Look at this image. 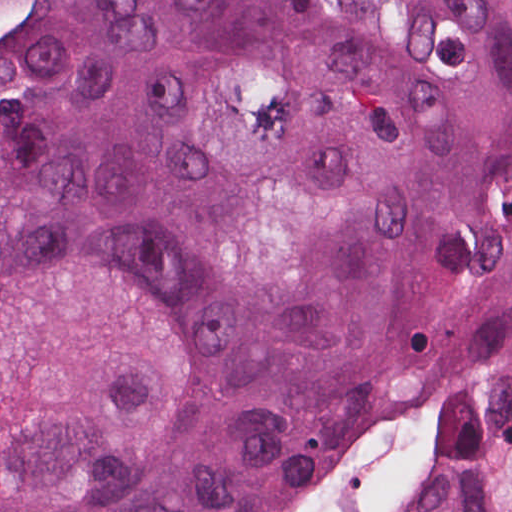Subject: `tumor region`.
<instances>
[{"label":"tumor region","instance_id":"1","mask_svg":"<svg viewBox=\"0 0 512 512\" xmlns=\"http://www.w3.org/2000/svg\"><path fill=\"white\" fill-rule=\"evenodd\" d=\"M0 512H512V0H17Z\"/></svg>","mask_w":512,"mask_h":512}]
</instances>
